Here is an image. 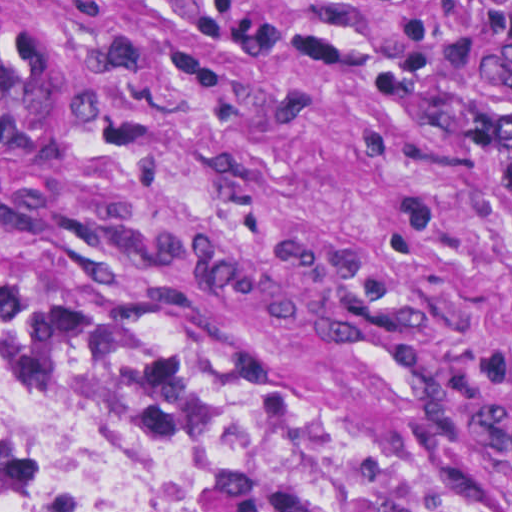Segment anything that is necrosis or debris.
Segmentation results:
<instances>
[{"instance_id":"4bbe7bcc","label":"necrosis or debris","mask_w":512,"mask_h":512,"mask_svg":"<svg viewBox=\"0 0 512 512\" xmlns=\"http://www.w3.org/2000/svg\"><path fill=\"white\" fill-rule=\"evenodd\" d=\"M125 452V421L79 389L0 371V477L57 499L78 496Z\"/></svg>"}]
</instances>
